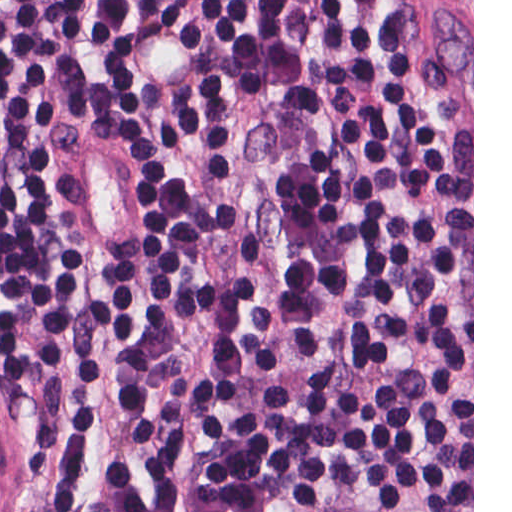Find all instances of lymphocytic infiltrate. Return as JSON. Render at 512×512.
Masks as SVG:
<instances>
[{
    "label": "lymphocytic infiltrate",
    "instance_id": "obj_1",
    "mask_svg": "<svg viewBox=\"0 0 512 512\" xmlns=\"http://www.w3.org/2000/svg\"><path fill=\"white\" fill-rule=\"evenodd\" d=\"M0 372L45 512H472L431 0H0Z\"/></svg>",
    "mask_w": 512,
    "mask_h": 512
}]
</instances>
